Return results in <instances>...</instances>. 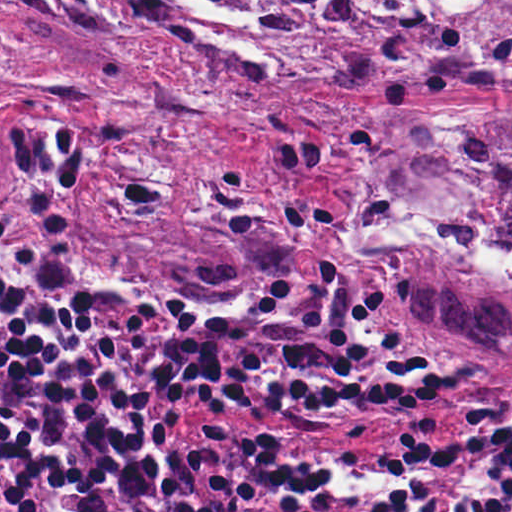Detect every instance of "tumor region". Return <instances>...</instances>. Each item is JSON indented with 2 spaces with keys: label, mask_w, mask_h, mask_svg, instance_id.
I'll return each mask as SVG.
<instances>
[{
  "label": "tumor region",
  "mask_w": 512,
  "mask_h": 512,
  "mask_svg": "<svg viewBox=\"0 0 512 512\" xmlns=\"http://www.w3.org/2000/svg\"><path fill=\"white\" fill-rule=\"evenodd\" d=\"M136 10L142 0H101ZM303 27L320 67L356 64L385 104L345 111L357 134V189L343 248L423 323L484 341L512 360V115L413 109L512 90V71L422 63L410 48L329 23L319 1L206 0ZM152 13L165 18L160 4ZM0 204L34 227L48 291L82 268L66 198L18 108L0 106ZM228 275L179 265L155 285L230 286ZM154 285V286H155Z\"/></svg>",
  "instance_id": "e687c5a6"
}]
</instances>
